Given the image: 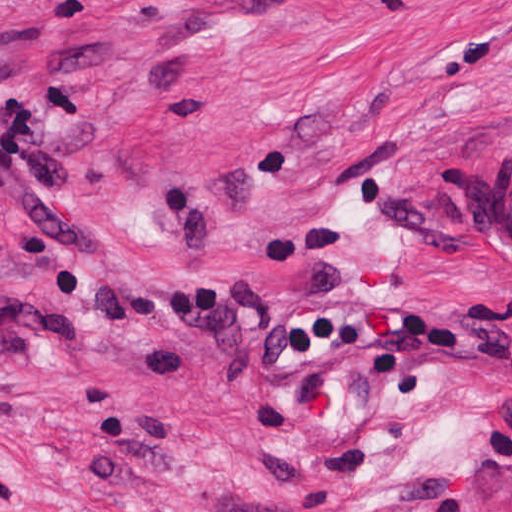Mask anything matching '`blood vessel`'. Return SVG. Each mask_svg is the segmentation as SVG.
Returning <instances> with one entry per match:
<instances>
[{
  "mask_svg": "<svg viewBox=\"0 0 512 512\" xmlns=\"http://www.w3.org/2000/svg\"><path fill=\"white\" fill-rule=\"evenodd\" d=\"M473 205L504 234L512 249V153L490 156L476 171Z\"/></svg>",
  "mask_w": 512,
  "mask_h": 512,
  "instance_id": "obj_1",
  "label": "blood vessel"
}]
</instances>
